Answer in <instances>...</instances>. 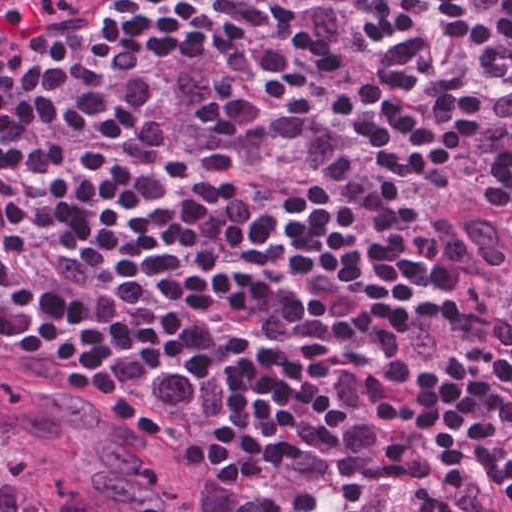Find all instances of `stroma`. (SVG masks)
<instances>
[{"mask_svg":"<svg viewBox=\"0 0 512 512\" xmlns=\"http://www.w3.org/2000/svg\"><path fill=\"white\" fill-rule=\"evenodd\" d=\"M22 1L25 4L24 17H23V19H24L30 15L46 12V11L53 10V9H56L59 7H76V6L84 4L86 2L95 1V0H22ZM127 1L130 2L131 4H133L135 7H137L141 11L147 13L148 15H149L150 10L153 8L144 0H127ZM431 189H433L439 193H442L443 195L453 197L456 199H459L457 196L472 199L484 211H486L487 213H490L491 215L496 216L494 213H492L490 211V209L487 206H485L480 201H478L477 199H475L474 197H472L470 195H466L463 193H459V192L452 191V190H446V189H436V188H431ZM489 300H506V299H489Z\"/></svg>","mask_w":512,"mask_h":512,"instance_id":"obj_1","label":"stroma"}]
</instances>
